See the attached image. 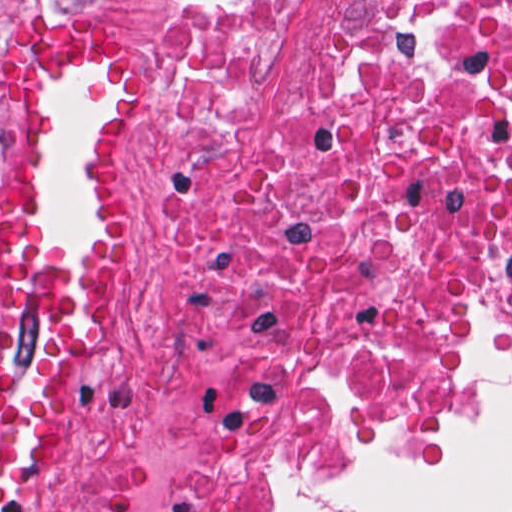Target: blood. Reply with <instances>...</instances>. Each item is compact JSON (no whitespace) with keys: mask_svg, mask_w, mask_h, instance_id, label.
<instances>
[{"mask_svg":"<svg viewBox=\"0 0 512 512\" xmlns=\"http://www.w3.org/2000/svg\"><path fill=\"white\" fill-rule=\"evenodd\" d=\"M131 48L76 21H34L0 41V512L25 498L75 442L78 365L107 337L136 223L118 178V138L132 103L113 100L84 157L92 265H57L40 251L29 198V125L40 89L57 79L131 84Z\"/></svg>","mask_w":512,"mask_h":512,"instance_id":"blood-1","label":"blood"}]
</instances>
